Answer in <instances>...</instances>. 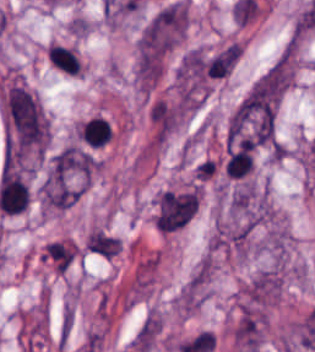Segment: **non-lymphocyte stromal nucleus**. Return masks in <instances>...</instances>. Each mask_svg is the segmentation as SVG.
<instances>
[{"label": "non-lymphocyte stromal nucleus", "mask_w": 315, "mask_h": 352, "mask_svg": "<svg viewBox=\"0 0 315 352\" xmlns=\"http://www.w3.org/2000/svg\"><path fill=\"white\" fill-rule=\"evenodd\" d=\"M5 116L11 148L38 154L48 143V119L39 98L19 83L5 91Z\"/></svg>", "instance_id": "non-lymphocyte-stromal-nucleus-1"}, {"label": "non-lymphocyte stromal nucleus", "mask_w": 315, "mask_h": 352, "mask_svg": "<svg viewBox=\"0 0 315 352\" xmlns=\"http://www.w3.org/2000/svg\"><path fill=\"white\" fill-rule=\"evenodd\" d=\"M199 204L197 187L172 191L159 199L157 218L165 232L183 227L195 214Z\"/></svg>", "instance_id": "non-lymphocyte-stromal-nucleus-2"}, {"label": "non-lymphocyte stromal nucleus", "mask_w": 315, "mask_h": 352, "mask_svg": "<svg viewBox=\"0 0 315 352\" xmlns=\"http://www.w3.org/2000/svg\"><path fill=\"white\" fill-rule=\"evenodd\" d=\"M264 318L256 309H242L234 331V340L249 352H258L262 344Z\"/></svg>", "instance_id": "non-lymphocyte-stromal-nucleus-4"}, {"label": "non-lymphocyte stromal nucleus", "mask_w": 315, "mask_h": 352, "mask_svg": "<svg viewBox=\"0 0 315 352\" xmlns=\"http://www.w3.org/2000/svg\"><path fill=\"white\" fill-rule=\"evenodd\" d=\"M74 313L67 302L61 312L59 326L57 330L58 349L64 350L68 344L71 332L73 330Z\"/></svg>", "instance_id": "non-lymphocyte-stromal-nucleus-6"}, {"label": "non-lymphocyte stromal nucleus", "mask_w": 315, "mask_h": 352, "mask_svg": "<svg viewBox=\"0 0 315 352\" xmlns=\"http://www.w3.org/2000/svg\"><path fill=\"white\" fill-rule=\"evenodd\" d=\"M97 164V158L87 148L66 145L53 154L51 172L64 178H89Z\"/></svg>", "instance_id": "non-lymphocyte-stromal-nucleus-3"}, {"label": "non-lymphocyte stromal nucleus", "mask_w": 315, "mask_h": 352, "mask_svg": "<svg viewBox=\"0 0 315 352\" xmlns=\"http://www.w3.org/2000/svg\"><path fill=\"white\" fill-rule=\"evenodd\" d=\"M80 192L79 187L50 172L42 183L41 199L52 208L67 209L77 201Z\"/></svg>", "instance_id": "non-lymphocyte-stromal-nucleus-5"}]
</instances>
